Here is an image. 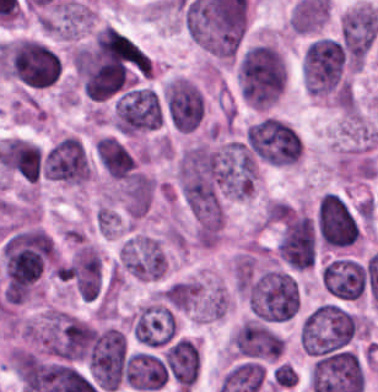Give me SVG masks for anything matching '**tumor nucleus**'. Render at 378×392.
<instances>
[{
	"mask_svg": "<svg viewBox=\"0 0 378 392\" xmlns=\"http://www.w3.org/2000/svg\"><path fill=\"white\" fill-rule=\"evenodd\" d=\"M358 331L359 318L353 312L326 302L303 318L299 329L300 344L315 360L347 351Z\"/></svg>",
	"mask_w": 378,
	"mask_h": 392,
	"instance_id": "1",
	"label": "tumor nucleus"
},
{
	"mask_svg": "<svg viewBox=\"0 0 378 392\" xmlns=\"http://www.w3.org/2000/svg\"><path fill=\"white\" fill-rule=\"evenodd\" d=\"M286 79L284 56L275 46L258 43L240 60V88L252 108L268 109L284 92Z\"/></svg>",
	"mask_w": 378,
	"mask_h": 392,
	"instance_id": "2",
	"label": "tumor nucleus"
},
{
	"mask_svg": "<svg viewBox=\"0 0 378 392\" xmlns=\"http://www.w3.org/2000/svg\"><path fill=\"white\" fill-rule=\"evenodd\" d=\"M244 146L258 159L274 166H291L299 161L301 138L279 117L262 114L245 125Z\"/></svg>",
	"mask_w": 378,
	"mask_h": 392,
	"instance_id": "3",
	"label": "tumor nucleus"
},
{
	"mask_svg": "<svg viewBox=\"0 0 378 392\" xmlns=\"http://www.w3.org/2000/svg\"><path fill=\"white\" fill-rule=\"evenodd\" d=\"M39 340L46 354L62 359H81L91 347V326L65 310L46 308Z\"/></svg>",
	"mask_w": 378,
	"mask_h": 392,
	"instance_id": "4",
	"label": "tumor nucleus"
},
{
	"mask_svg": "<svg viewBox=\"0 0 378 392\" xmlns=\"http://www.w3.org/2000/svg\"><path fill=\"white\" fill-rule=\"evenodd\" d=\"M245 296L249 308L262 319H282L296 311L298 287L284 270L267 268L250 282Z\"/></svg>",
	"mask_w": 378,
	"mask_h": 392,
	"instance_id": "5",
	"label": "tumor nucleus"
},
{
	"mask_svg": "<svg viewBox=\"0 0 378 392\" xmlns=\"http://www.w3.org/2000/svg\"><path fill=\"white\" fill-rule=\"evenodd\" d=\"M114 124L120 134L131 136L158 129L161 110L157 95L147 89L127 91L115 103Z\"/></svg>",
	"mask_w": 378,
	"mask_h": 392,
	"instance_id": "6",
	"label": "tumor nucleus"
},
{
	"mask_svg": "<svg viewBox=\"0 0 378 392\" xmlns=\"http://www.w3.org/2000/svg\"><path fill=\"white\" fill-rule=\"evenodd\" d=\"M316 246L314 222L307 214L294 212L279 234L276 255L297 270L310 268Z\"/></svg>",
	"mask_w": 378,
	"mask_h": 392,
	"instance_id": "7",
	"label": "tumor nucleus"
},
{
	"mask_svg": "<svg viewBox=\"0 0 378 392\" xmlns=\"http://www.w3.org/2000/svg\"><path fill=\"white\" fill-rule=\"evenodd\" d=\"M317 229L326 246L342 247L359 238V225L339 194L328 192L319 200Z\"/></svg>",
	"mask_w": 378,
	"mask_h": 392,
	"instance_id": "8",
	"label": "tumor nucleus"
},
{
	"mask_svg": "<svg viewBox=\"0 0 378 392\" xmlns=\"http://www.w3.org/2000/svg\"><path fill=\"white\" fill-rule=\"evenodd\" d=\"M45 176L71 183H84L91 177L90 163L78 137L66 136L45 153Z\"/></svg>",
	"mask_w": 378,
	"mask_h": 392,
	"instance_id": "9",
	"label": "tumor nucleus"
},
{
	"mask_svg": "<svg viewBox=\"0 0 378 392\" xmlns=\"http://www.w3.org/2000/svg\"><path fill=\"white\" fill-rule=\"evenodd\" d=\"M164 98L175 129L193 131L199 125L204 101L192 81L176 78L164 89Z\"/></svg>",
	"mask_w": 378,
	"mask_h": 392,
	"instance_id": "10",
	"label": "tumor nucleus"
},
{
	"mask_svg": "<svg viewBox=\"0 0 378 392\" xmlns=\"http://www.w3.org/2000/svg\"><path fill=\"white\" fill-rule=\"evenodd\" d=\"M321 277L326 291L348 300L357 299L364 291L361 268L352 258L337 257L326 264Z\"/></svg>",
	"mask_w": 378,
	"mask_h": 392,
	"instance_id": "11",
	"label": "tumor nucleus"
},
{
	"mask_svg": "<svg viewBox=\"0 0 378 392\" xmlns=\"http://www.w3.org/2000/svg\"><path fill=\"white\" fill-rule=\"evenodd\" d=\"M68 271L79 296L91 302L101 286V260L97 249L82 245L73 253Z\"/></svg>",
	"mask_w": 378,
	"mask_h": 392,
	"instance_id": "12",
	"label": "tumor nucleus"
},
{
	"mask_svg": "<svg viewBox=\"0 0 378 392\" xmlns=\"http://www.w3.org/2000/svg\"><path fill=\"white\" fill-rule=\"evenodd\" d=\"M164 363L176 385L189 389L198 374L197 345L186 338H179L166 348Z\"/></svg>",
	"mask_w": 378,
	"mask_h": 392,
	"instance_id": "13",
	"label": "tumor nucleus"
},
{
	"mask_svg": "<svg viewBox=\"0 0 378 392\" xmlns=\"http://www.w3.org/2000/svg\"><path fill=\"white\" fill-rule=\"evenodd\" d=\"M95 148L101 164L114 178L126 179L131 176L135 166L134 159L117 140L100 138Z\"/></svg>",
	"mask_w": 378,
	"mask_h": 392,
	"instance_id": "14",
	"label": "tumor nucleus"
}]
</instances>
